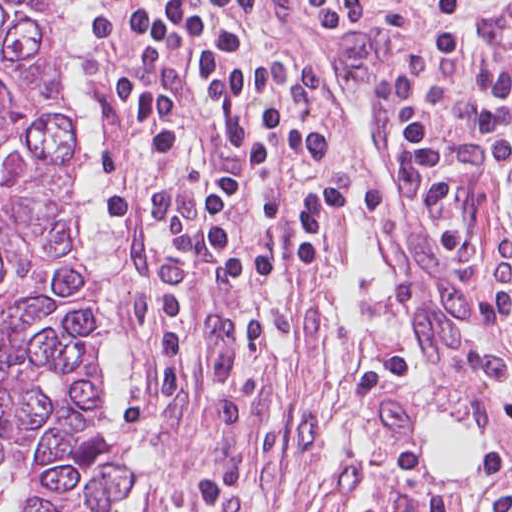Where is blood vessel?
<instances>
[{
  "label": "blood vessel",
  "instance_id": "8fb6f2fc",
  "mask_svg": "<svg viewBox=\"0 0 512 512\" xmlns=\"http://www.w3.org/2000/svg\"><path fill=\"white\" fill-rule=\"evenodd\" d=\"M284 21L321 93L358 143L419 271L434 316L500 428L503 386L512 385V366L501 351L509 329L494 302L462 273L412 153L402 154L391 145L379 102V56L369 24L351 17L286 20V12Z\"/></svg>",
  "mask_w": 512,
  "mask_h": 512
}]
</instances>
